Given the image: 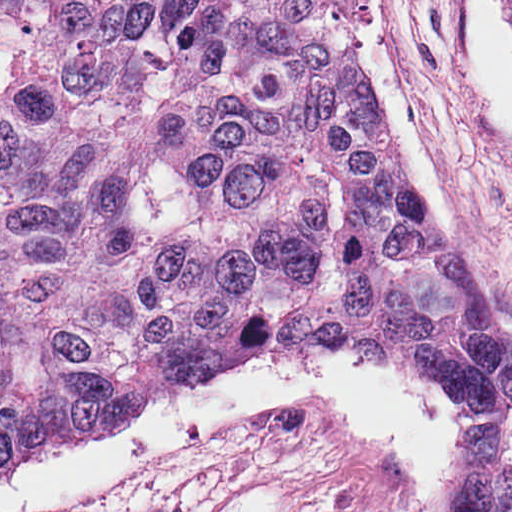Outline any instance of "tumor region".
Wrapping results in <instances>:
<instances>
[{"label": "tumor region", "instance_id": "obj_1", "mask_svg": "<svg viewBox=\"0 0 512 512\" xmlns=\"http://www.w3.org/2000/svg\"><path fill=\"white\" fill-rule=\"evenodd\" d=\"M196 376L31 0H0V480Z\"/></svg>", "mask_w": 512, "mask_h": 512}]
</instances>
